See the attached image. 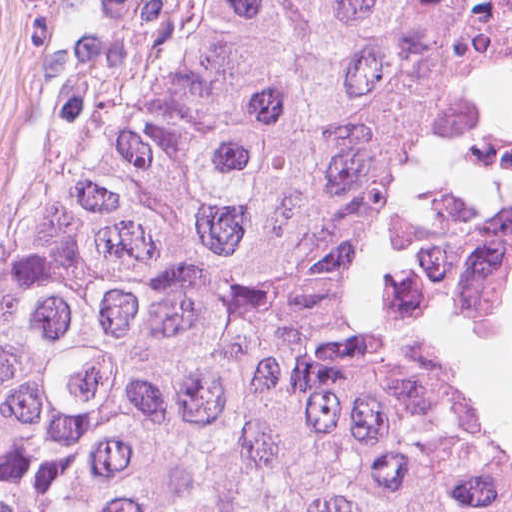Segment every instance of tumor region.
Masks as SVG:
<instances>
[{
	"label": "tumor region",
	"mask_w": 512,
	"mask_h": 512,
	"mask_svg": "<svg viewBox=\"0 0 512 512\" xmlns=\"http://www.w3.org/2000/svg\"><path fill=\"white\" fill-rule=\"evenodd\" d=\"M424 0H136L0 300V512H512V420L392 338L360 131Z\"/></svg>",
	"instance_id": "tumor-region-1"
}]
</instances>
